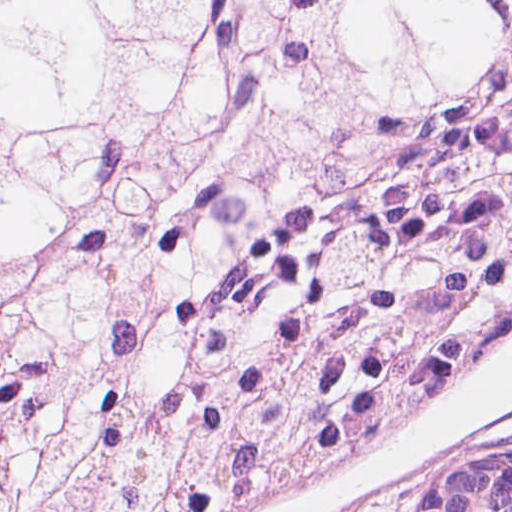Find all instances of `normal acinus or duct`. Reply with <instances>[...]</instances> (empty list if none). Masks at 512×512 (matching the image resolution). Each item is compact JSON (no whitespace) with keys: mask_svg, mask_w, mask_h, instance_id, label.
<instances>
[{"mask_svg":"<svg viewBox=\"0 0 512 512\" xmlns=\"http://www.w3.org/2000/svg\"><path fill=\"white\" fill-rule=\"evenodd\" d=\"M413 512H512L511 446L455 459L428 475Z\"/></svg>","mask_w":512,"mask_h":512,"instance_id":"obj_1","label":"normal acinus or duct"}]
</instances>
